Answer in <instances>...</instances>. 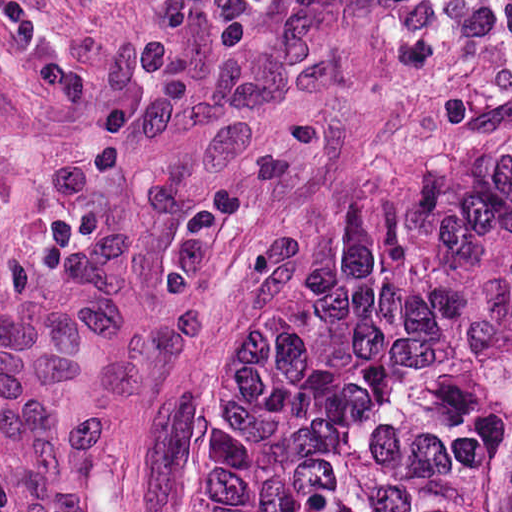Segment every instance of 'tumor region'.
<instances>
[{
	"label": "tumor region",
	"instance_id": "1",
	"mask_svg": "<svg viewBox=\"0 0 512 512\" xmlns=\"http://www.w3.org/2000/svg\"><path fill=\"white\" fill-rule=\"evenodd\" d=\"M185 512H512V135L250 262Z\"/></svg>",
	"mask_w": 512,
	"mask_h": 512
}]
</instances>
